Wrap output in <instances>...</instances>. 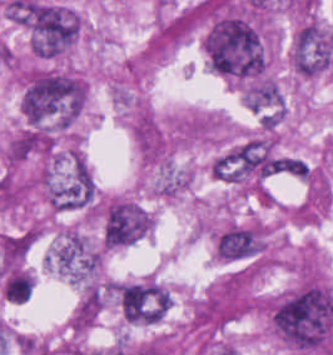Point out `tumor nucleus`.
<instances>
[{"mask_svg": "<svg viewBox=\"0 0 333 355\" xmlns=\"http://www.w3.org/2000/svg\"><path fill=\"white\" fill-rule=\"evenodd\" d=\"M204 53L220 75L237 82L260 78L265 64L263 37L245 17L217 13L208 23Z\"/></svg>", "mask_w": 333, "mask_h": 355, "instance_id": "2f306a5c", "label": "tumor nucleus"}, {"mask_svg": "<svg viewBox=\"0 0 333 355\" xmlns=\"http://www.w3.org/2000/svg\"><path fill=\"white\" fill-rule=\"evenodd\" d=\"M85 104V83L64 72L31 71L23 84L22 117L30 126L62 131Z\"/></svg>", "mask_w": 333, "mask_h": 355, "instance_id": "8643909e", "label": "tumor nucleus"}, {"mask_svg": "<svg viewBox=\"0 0 333 355\" xmlns=\"http://www.w3.org/2000/svg\"><path fill=\"white\" fill-rule=\"evenodd\" d=\"M80 29V14L75 9L31 1L27 20L31 52L42 58H55L71 47Z\"/></svg>", "mask_w": 333, "mask_h": 355, "instance_id": "5ab6c2c4", "label": "tumor nucleus"}, {"mask_svg": "<svg viewBox=\"0 0 333 355\" xmlns=\"http://www.w3.org/2000/svg\"><path fill=\"white\" fill-rule=\"evenodd\" d=\"M42 176L53 210H85L95 202L93 179L82 156L56 165Z\"/></svg>", "mask_w": 333, "mask_h": 355, "instance_id": "2cbd58db", "label": "tumor nucleus"}, {"mask_svg": "<svg viewBox=\"0 0 333 355\" xmlns=\"http://www.w3.org/2000/svg\"><path fill=\"white\" fill-rule=\"evenodd\" d=\"M151 229V215L124 197L109 200L103 209L101 243L110 250L133 245Z\"/></svg>", "mask_w": 333, "mask_h": 355, "instance_id": "3d1891a8", "label": "tumor nucleus"}, {"mask_svg": "<svg viewBox=\"0 0 333 355\" xmlns=\"http://www.w3.org/2000/svg\"><path fill=\"white\" fill-rule=\"evenodd\" d=\"M333 50V28L306 22L294 35L290 64L303 77H313L327 67Z\"/></svg>", "mask_w": 333, "mask_h": 355, "instance_id": "2083b535", "label": "tumor nucleus"}, {"mask_svg": "<svg viewBox=\"0 0 333 355\" xmlns=\"http://www.w3.org/2000/svg\"><path fill=\"white\" fill-rule=\"evenodd\" d=\"M215 244L219 257L243 260L262 249L263 235L259 229L250 226L232 225L218 235Z\"/></svg>", "mask_w": 333, "mask_h": 355, "instance_id": "8087334f", "label": "tumor nucleus"}]
</instances>
